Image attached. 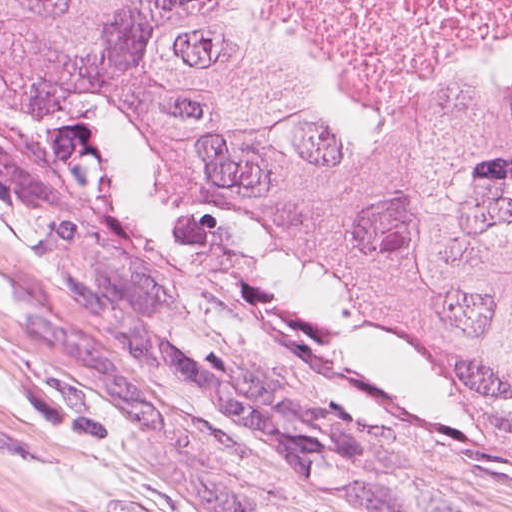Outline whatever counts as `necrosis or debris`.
Instances as JSON below:
<instances>
[{"instance_id": "1", "label": "necrosis or debris", "mask_w": 512, "mask_h": 512, "mask_svg": "<svg viewBox=\"0 0 512 512\" xmlns=\"http://www.w3.org/2000/svg\"><path fill=\"white\" fill-rule=\"evenodd\" d=\"M339 77L390 81L451 46L512 43V0H273Z\"/></svg>"}]
</instances>
